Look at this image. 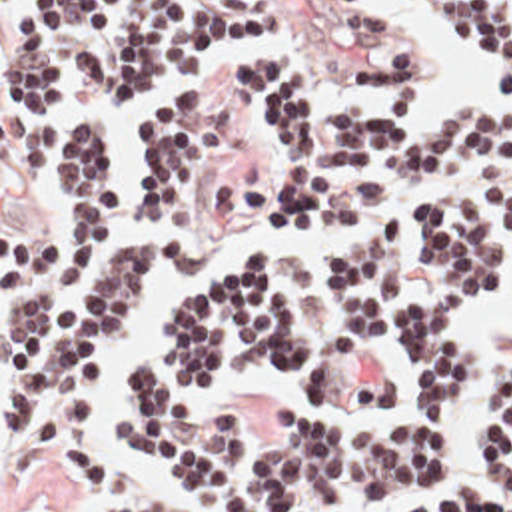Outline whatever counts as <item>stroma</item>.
Masks as SVG:
<instances>
[{
	"instance_id": "35a3bbf8",
	"label": "stroma",
	"mask_w": 512,
	"mask_h": 512,
	"mask_svg": "<svg viewBox=\"0 0 512 512\" xmlns=\"http://www.w3.org/2000/svg\"><path fill=\"white\" fill-rule=\"evenodd\" d=\"M421 17L439 33L459 41L475 61V77L503 85L497 69L485 59L477 41L435 0H393ZM12 25H2L0 0V512H104L122 504H170L176 512H212L200 502L184 482L146 468L138 458L122 452L106 440L104 426L118 416L130 414V406L120 390V364L138 356L162 358L164 344L174 332L180 314L204 286L236 268L244 256L260 250H288L319 242L337 232L349 230L355 216L327 222L323 226L288 236H252L272 202L282 178V137L280 129L266 121L260 111L240 93L238 69L242 63L266 49H294L301 55L309 75L311 91L321 107H373L399 99L397 91L363 83L353 61L395 43L409 33L403 27L351 35L337 31L329 19L303 0H282V31L266 39L246 57L226 61L204 79L218 95L220 105L236 127V146L218 162L210 180L208 196L182 232H166V238L180 246V264L158 272L154 294L142 314L132 340L98 358V396L92 418V448L98 458L122 468L136 470L142 492L126 502H84L74 488V480L64 460L48 446L34 458L20 460L2 446V396L10 374H2V312L24 288L40 264L52 230V178L30 180L20 168V152L2 137V43ZM415 35V33H413ZM417 39V127L439 123L459 105H443L431 85L429 47ZM465 103H473L471 97ZM503 121V119H501ZM505 123V121H503ZM507 125V123H505ZM507 129H512L507 125ZM138 148L112 152L120 182L122 200L136 236H148L134 206ZM142 212V202H140ZM250 238V240H248ZM511 242L512 232L507 234ZM385 362L395 366L405 378L401 398L377 412H337L315 410L325 424H383L399 414L411 390V352L399 340L379 346ZM166 366L184 380L182 372ZM194 396L214 408H250V428L262 430L270 424L282 426L278 406L301 400L294 380L274 372L264 364H248L228 376L222 384ZM347 512H373L365 502L351 500Z\"/></svg>"
}]
</instances>
